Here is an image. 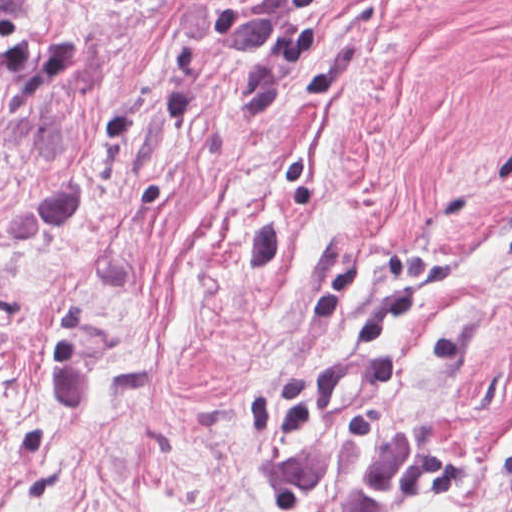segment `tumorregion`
<instances>
[{"mask_svg":"<svg viewBox=\"0 0 512 512\" xmlns=\"http://www.w3.org/2000/svg\"><path fill=\"white\" fill-rule=\"evenodd\" d=\"M27 1H0V14H26ZM280 1H225L210 27L221 57H270L278 40ZM414 427H398L383 448L321 432L278 439L269 470L285 505L297 512H404L421 447Z\"/></svg>","mask_w":512,"mask_h":512,"instance_id":"1","label":"tumor region"}]
</instances>
